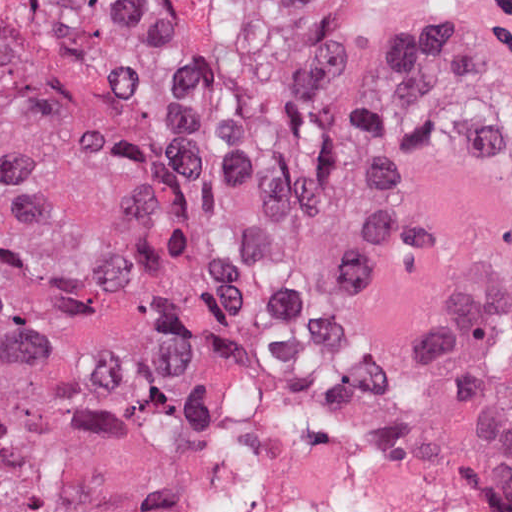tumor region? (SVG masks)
Masks as SVG:
<instances>
[{"instance_id":"tumor-region-1","label":"tumor region","mask_w":512,"mask_h":512,"mask_svg":"<svg viewBox=\"0 0 512 512\" xmlns=\"http://www.w3.org/2000/svg\"><path fill=\"white\" fill-rule=\"evenodd\" d=\"M246 347L364 374L512 504V80L256 0H0V512H228Z\"/></svg>"}]
</instances>
